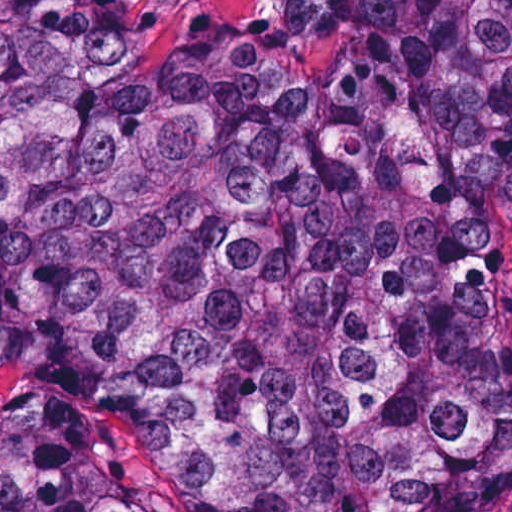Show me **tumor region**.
I'll list each match as a JSON object with an SVG mask.
<instances>
[{
  "instance_id": "e687c5a6",
  "label": "tumor region",
  "mask_w": 512,
  "mask_h": 512,
  "mask_svg": "<svg viewBox=\"0 0 512 512\" xmlns=\"http://www.w3.org/2000/svg\"><path fill=\"white\" fill-rule=\"evenodd\" d=\"M0 0V386L198 512L512 505V0ZM0 512H150L33 430Z\"/></svg>"
}]
</instances>
